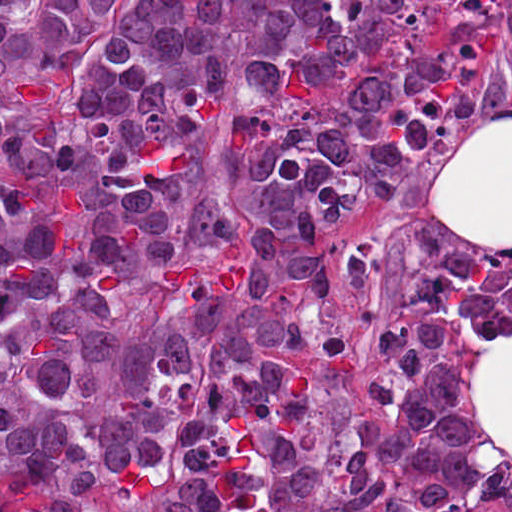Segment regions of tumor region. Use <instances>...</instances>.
I'll use <instances>...</instances> for the list:
<instances>
[{
	"mask_svg": "<svg viewBox=\"0 0 512 512\" xmlns=\"http://www.w3.org/2000/svg\"><path fill=\"white\" fill-rule=\"evenodd\" d=\"M512 0H0V512H480L512 260L405 284L367 416L331 247L483 105Z\"/></svg>",
	"mask_w": 512,
	"mask_h": 512,
	"instance_id": "obj_1",
	"label": "tumor region"
}]
</instances>
